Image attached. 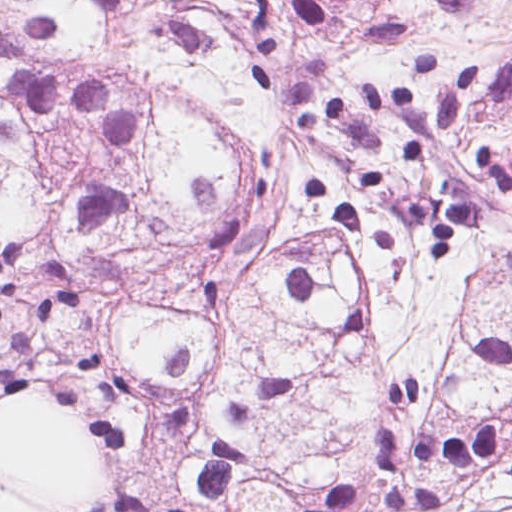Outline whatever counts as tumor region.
I'll list each match as a JSON object with an SVG mask.
<instances>
[{
    "instance_id": "1",
    "label": "tumor region",
    "mask_w": 512,
    "mask_h": 512,
    "mask_svg": "<svg viewBox=\"0 0 512 512\" xmlns=\"http://www.w3.org/2000/svg\"><path fill=\"white\" fill-rule=\"evenodd\" d=\"M0 399L139 512H295L391 379L512 404V0H0Z\"/></svg>"
}]
</instances>
